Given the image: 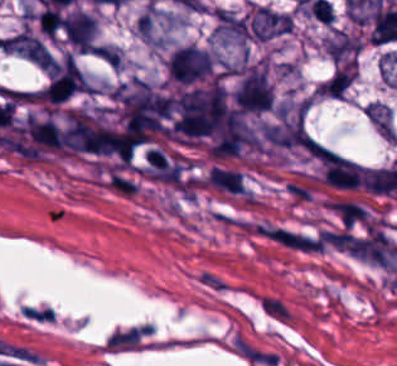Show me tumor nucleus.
I'll list each match as a JSON object with an SVG mask.
<instances>
[{
    "instance_id": "5ab6c2c4",
    "label": "tumor nucleus",
    "mask_w": 397,
    "mask_h": 366,
    "mask_svg": "<svg viewBox=\"0 0 397 366\" xmlns=\"http://www.w3.org/2000/svg\"><path fill=\"white\" fill-rule=\"evenodd\" d=\"M365 112L369 120L385 139H397V128L393 109L379 100L367 102Z\"/></svg>"
},
{
    "instance_id": "8643909e",
    "label": "tumor nucleus",
    "mask_w": 397,
    "mask_h": 366,
    "mask_svg": "<svg viewBox=\"0 0 397 366\" xmlns=\"http://www.w3.org/2000/svg\"><path fill=\"white\" fill-rule=\"evenodd\" d=\"M326 37L339 64L345 68H355L359 35L354 30L332 25Z\"/></svg>"
},
{
    "instance_id": "2f306a5c",
    "label": "tumor nucleus",
    "mask_w": 397,
    "mask_h": 366,
    "mask_svg": "<svg viewBox=\"0 0 397 366\" xmlns=\"http://www.w3.org/2000/svg\"><path fill=\"white\" fill-rule=\"evenodd\" d=\"M85 92L88 82L77 63L66 54L47 71L40 94L52 102H62Z\"/></svg>"
}]
</instances>
